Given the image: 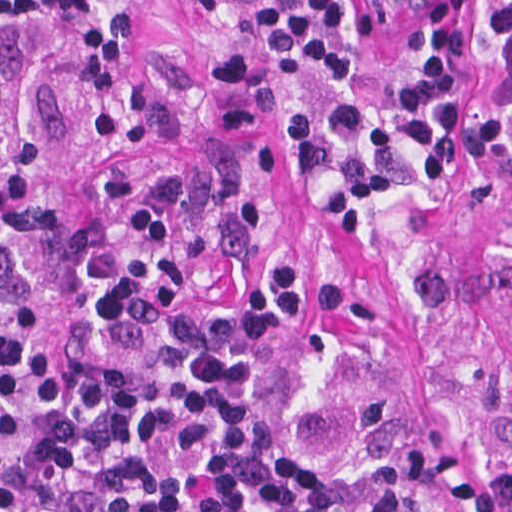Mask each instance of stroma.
Listing matches in <instances>:
<instances>
[{
    "label": "stroma",
    "mask_w": 512,
    "mask_h": 512,
    "mask_svg": "<svg viewBox=\"0 0 512 512\" xmlns=\"http://www.w3.org/2000/svg\"><path fill=\"white\" fill-rule=\"evenodd\" d=\"M125 12L110 101L79 75L50 0L41 22L0 8V92L39 145V182L0 244V312L51 351L168 346L184 301L251 298L277 260L310 267L313 318L260 366V398L328 460L444 512H512V79L464 0V117L454 168L424 179L404 92L427 0H344L359 60L323 77L215 13L165 0ZM351 98L392 187L360 231L330 234L316 196L346 168L296 172L283 120L321 123ZM172 222V251L137 310L92 303L127 261L137 202Z\"/></svg>",
    "instance_id": "obj_1"
}]
</instances>
